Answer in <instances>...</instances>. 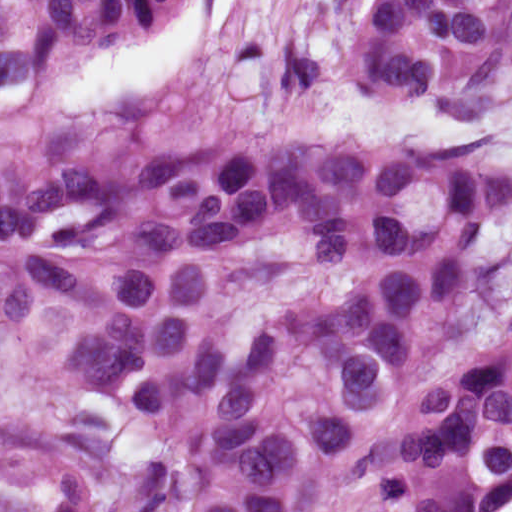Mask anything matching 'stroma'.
I'll use <instances>...</instances> for the list:
<instances>
[{
  "mask_svg": "<svg viewBox=\"0 0 512 512\" xmlns=\"http://www.w3.org/2000/svg\"><path fill=\"white\" fill-rule=\"evenodd\" d=\"M368 1L168 0L68 58L50 103L80 152L281 131L397 150L471 143L464 120L369 74ZM48 409L42 375L0 354V430L43 423Z\"/></svg>",
  "mask_w": 512,
  "mask_h": 512,
  "instance_id": "obj_1",
  "label": "stroma"
}]
</instances>
